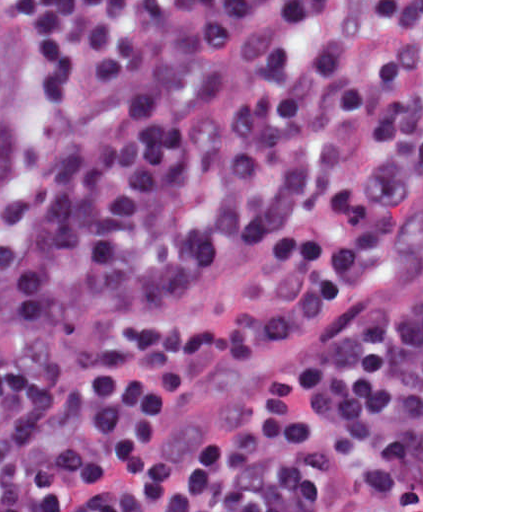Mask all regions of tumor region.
Returning a JSON list of instances; mask_svg holds the SVG:
<instances>
[{"label": "tumor region", "mask_w": 512, "mask_h": 512, "mask_svg": "<svg viewBox=\"0 0 512 512\" xmlns=\"http://www.w3.org/2000/svg\"><path fill=\"white\" fill-rule=\"evenodd\" d=\"M19 33L10 0H0V205L15 172Z\"/></svg>", "instance_id": "e687c5a6"}]
</instances>
